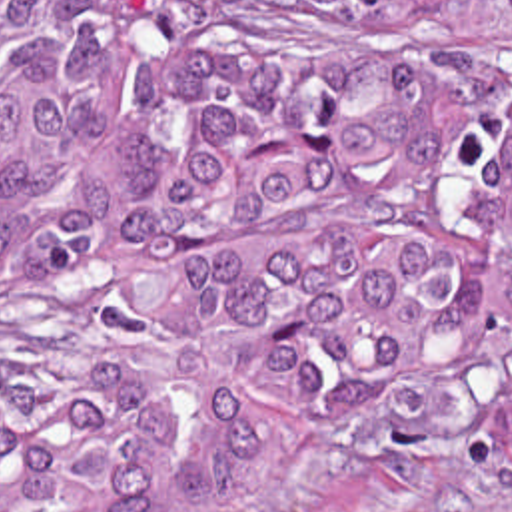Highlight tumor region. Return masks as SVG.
<instances>
[{
    "label": "tumor region",
    "mask_w": 512,
    "mask_h": 512,
    "mask_svg": "<svg viewBox=\"0 0 512 512\" xmlns=\"http://www.w3.org/2000/svg\"><path fill=\"white\" fill-rule=\"evenodd\" d=\"M0 289L116 307L0 394V512L446 414L512 370V0H0Z\"/></svg>",
    "instance_id": "tumor-region-1"
}]
</instances>
